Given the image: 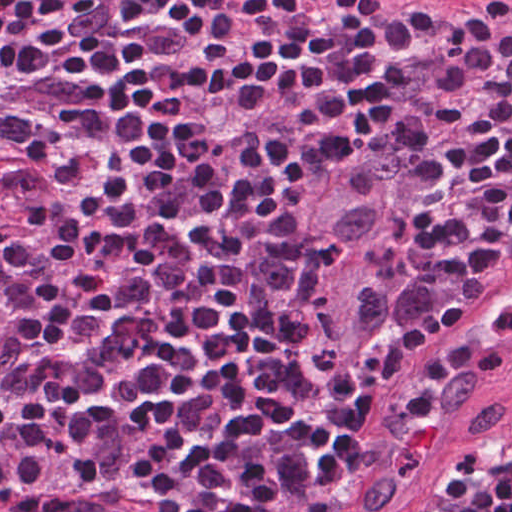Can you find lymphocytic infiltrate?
Listing matches in <instances>:
<instances>
[{
  "label": "lymphocytic infiltrate",
  "instance_id": "lymphocytic-infiltrate-1",
  "mask_svg": "<svg viewBox=\"0 0 512 512\" xmlns=\"http://www.w3.org/2000/svg\"><path fill=\"white\" fill-rule=\"evenodd\" d=\"M436 131L426 276L468 294L512 258V20L0 0L21 211L0 224V492L43 510L34 487L144 480L170 512H326L387 377L459 301L316 391L269 266L329 158ZM449 505L512 512V432L461 458Z\"/></svg>",
  "mask_w": 512,
  "mask_h": 512
}]
</instances>
